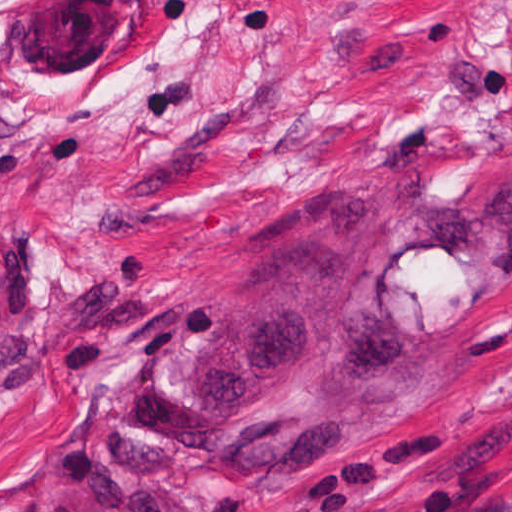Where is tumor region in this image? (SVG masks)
I'll return each mask as SVG.
<instances>
[{
	"mask_svg": "<svg viewBox=\"0 0 512 512\" xmlns=\"http://www.w3.org/2000/svg\"><path fill=\"white\" fill-rule=\"evenodd\" d=\"M512 4V0H509ZM244 229L234 296L170 308L75 406L47 462L90 512H201L164 479L317 472L446 404L479 312L512 288V187L465 211L332 181Z\"/></svg>",
	"mask_w": 512,
	"mask_h": 512,
	"instance_id": "e687c5a6",
	"label": "tumor region"
}]
</instances>
